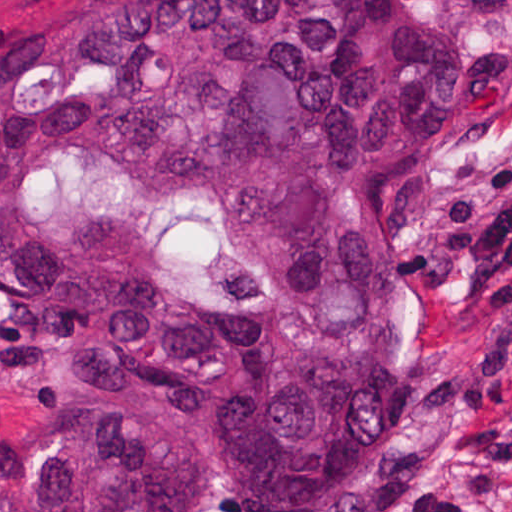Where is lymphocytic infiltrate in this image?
<instances>
[{"instance_id":"f902f5d3","label":"lymphocytic infiltrate","mask_w":512,"mask_h":512,"mask_svg":"<svg viewBox=\"0 0 512 512\" xmlns=\"http://www.w3.org/2000/svg\"><path fill=\"white\" fill-rule=\"evenodd\" d=\"M440 250L468 265V278L481 288L479 320L471 335L468 375L460 402L471 416L512 412V188L498 207L463 200L437 223ZM377 512H459L422 487L379 492Z\"/></svg>"}]
</instances>
